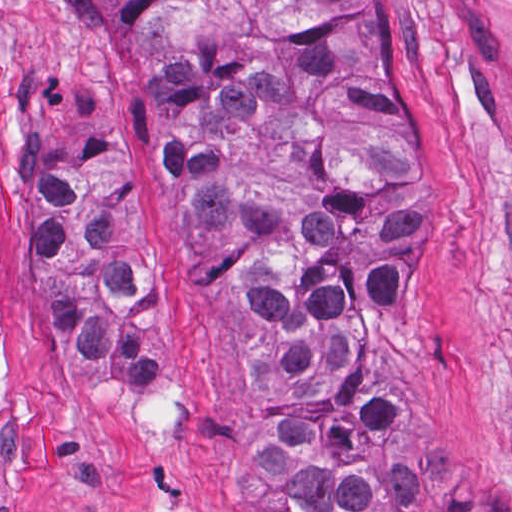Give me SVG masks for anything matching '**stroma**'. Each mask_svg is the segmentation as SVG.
<instances>
[{"instance_id": "1", "label": "stroma", "mask_w": 512, "mask_h": 512, "mask_svg": "<svg viewBox=\"0 0 512 512\" xmlns=\"http://www.w3.org/2000/svg\"><path fill=\"white\" fill-rule=\"evenodd\" d=\"M404 3L441 160L423 267L432 404L421 435L512 504V78L440 0ZM48 71L86 84L121 122L128 196L156 262L151 390L65 363L31 293L42 215L18 192L22 102L30 75ZM150 136L134 104L84 71L43 0H0V512H269L249 458L252 370L185 272Z\"/></svg>"}]
</instances>
